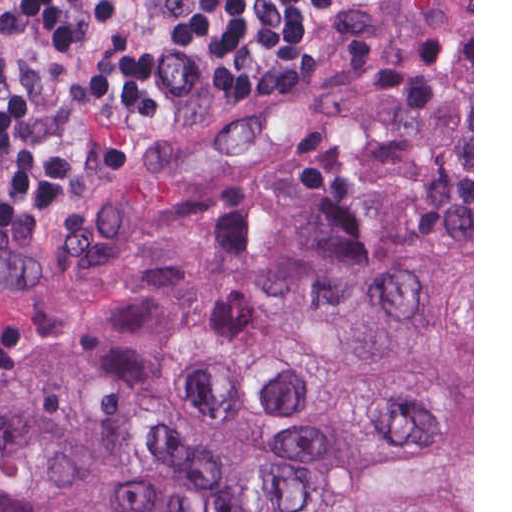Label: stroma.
Here are the masks:
<instances>
[{"instance_id": "1", "label": "stroma", "mask_w": 512, "mask_h": 512, "mask_svg": "<svg viewBox=\"0 0 512 512\" xmlns=\"http://www.w3.org/2000/svg\"><path fill=\"white\" fill-rule=\"evenodd\" d=\"M471 73L474 512V0H359L274 82L197 78L193 99L104 177L0 189V381L91 340L217 218L364 159L374 126Z\"/></svg>"}]
</instances>
